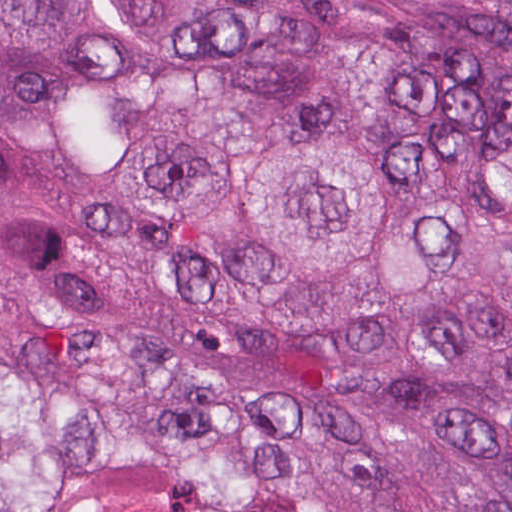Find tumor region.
Returning a JSON list of instances; mask_svg holds the SVG:
<instances>
[{"instance_id":"1","label":"tumor region","mask_w":512,"mask_h":512,"mask_svg":"<svg viewBox=\"0 0 512 512\" xmlns=\"http://www.w3.org/2000/svg\"><path fill=\"white\" fill-rule=\"evenodd\" d=\"M0 512H512V0H0Z\"/></svg>"}]
</instances>
